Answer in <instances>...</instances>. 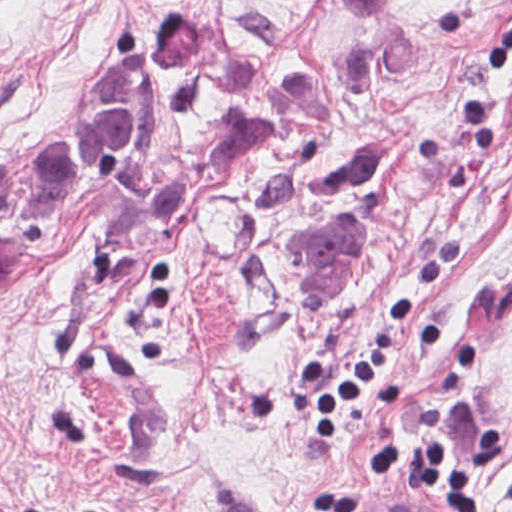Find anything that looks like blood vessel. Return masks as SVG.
Here are the masks:
<instances>
[{"mask_svg": "<svg viewBox=\"0 0 512 512\" xmlns=\"http://www.w3.org/2000/svg\"><path fill=\"white\" fill-rule=\"evenodd\" d=\"M355 512H453L436 499H400Z\"/></svg>", "mask_w": 512, "mask_h": 512, "instance_id": "obj_1", "label": "blood vessel"}]
</instances>
